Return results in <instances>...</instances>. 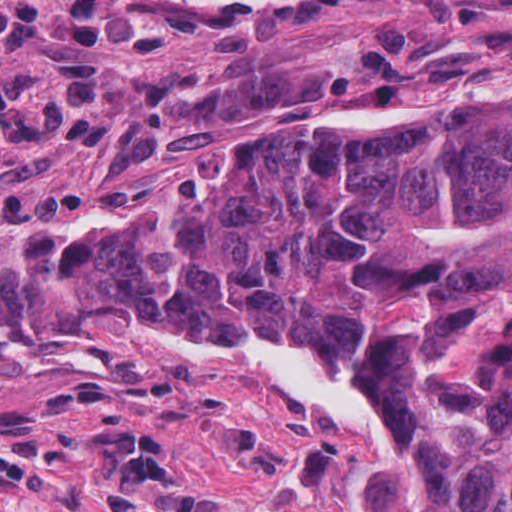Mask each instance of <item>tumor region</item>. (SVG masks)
I'll return each instance as SVG.
<instances>
[{"label": "tumor region", "instance_id": "e687c5a6", "mask_svg": "<svg viewBox=\"0 0 512 512\" xmlns=\"http://www.w3.org/2000/svg\"><path fill=\"white\" fill-rule=\"evenodd\" d=\"M0 1L2 17L22 0ZM168 132L117 165L138 166ZM101 190L38 191L1 207L0 228L19 218L18 250L62 296L193 355L295 325L331 338L394 382L381 512H512V92L268 155L221 199L30 249L21 218L68 224Z\"/></svg>", "mask_w": 512, "mask_h": 512}]
</instances>
